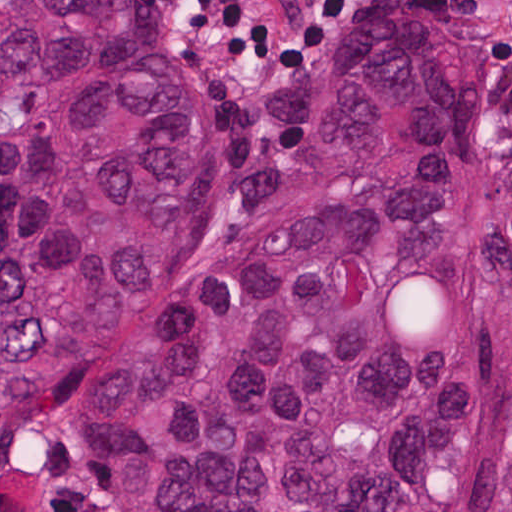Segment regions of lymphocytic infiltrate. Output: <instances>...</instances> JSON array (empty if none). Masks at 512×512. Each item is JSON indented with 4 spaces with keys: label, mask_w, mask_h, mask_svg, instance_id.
<instances>
[{
    "label": "lymphocytic infiltrate",
    "mask_w": 512,
    "mask_h": 512,
    "mask_svg": "<svg viewBox=\"0 0 512 512\" xmlns=\"http://www.w3.org/2000/svg\"><path fill=\"white\" fill-rule=\"evenodd\" d=\"M361 0H340L331 7L324 25L310 38L296 45H206L212 50L230 53L240 63L259 69H286L294 64L323 37L329 30L332 20L346 6ZM171 12V11H170ZM172 18L185 37H190L183 26L171 12Z\"/></svg>",
    "instance_id": "obj_1"
}]
</instances>
